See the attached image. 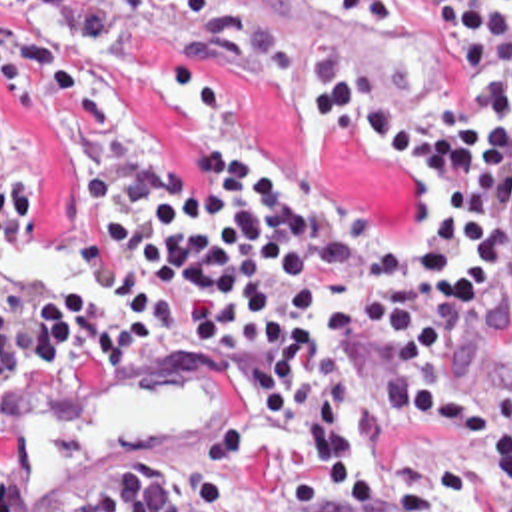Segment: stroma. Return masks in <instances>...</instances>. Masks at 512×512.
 Masks as SVG:
<instances>
[{
  "instance_id": "obj_1",
  "label": "stroma",
  "mask_w": 512,
  "mask_h": 512,
  "mask_svg": "<svg viewBox=\"0 0 512 512\" xmlns=\"http://www.w3.org/2000/svg\"><path fill=\"white\" fill-rule=\"evenodd\" d=\"M120 10L110 40L74 46L44 12L0 0V12L16 18L44 52L98 80L136 134L148 132L164 148L186 194L200 190L202 152L210 142L254 140L328 162L342 208L390 228L406 226V176L364 142L322 138L306 104L238 68L232 52L242 42H284L330 56L352 78L420 104L441 124L457 100L455 58L445 36L420 26L416 0H246L242 26L196 24L162 0H120ZM80 176L82 166L70 160L46 120L24 116L0 96V254L22 242H48L66 252V218ZM82 292L98 308L108 304L98 278L96 290Z\"/></svg>"
}]
</instances>
